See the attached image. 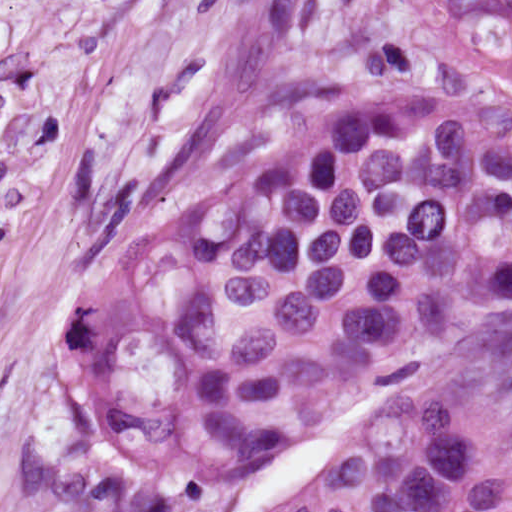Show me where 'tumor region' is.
Instances as JSON below:
<instances>
[{
    "label": "tumor region",
    "mask_w": 512,
    "mask_h": 512,
    "mask_svg": "<svg viewBox=\"0 0 512 512\" xmlns=\"http://www.w3.org/2000/svg\"><path fill=\"white\" fill-rule=\"evenodd\" d=\"M497 77L371 86L123 247L33 340L26 512H180L353 427L296 512H512L454 394L512 368V0H431Z\"/></svg>",
    "instance_id": "e687c5a6"
}]
</instances>
